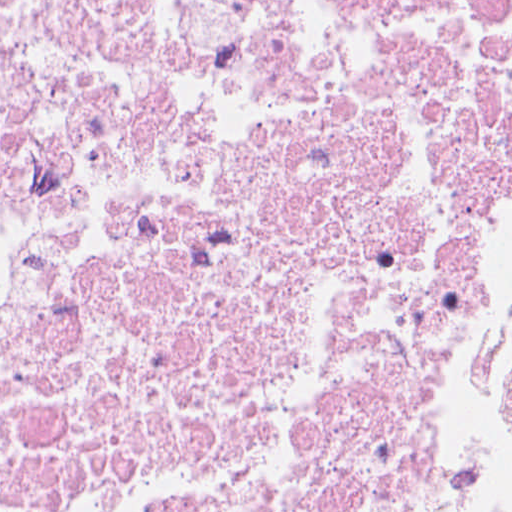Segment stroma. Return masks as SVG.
I'll use <instances>...</instances> for the list:
<instances>
[{
    "label": "stroma",
    "mask_w": 512,
    "mask_h": 512,
    "mask_svg": "<svg viewBox=\"0 0 512 512\" xmlns=\"http://www.w3.org/2000/svg\"><path fill=\"white\" fill-rule=\"evenodd\" d=\"M507 138L501 71V0H470L462 60V268L431 446L415 482L411 512H433V464L453 430L464 339V236L499 175ZM512 512V503L503 511Z\"/></svg>",
    "instance_id": "stroma-1"
}]
</instances>
